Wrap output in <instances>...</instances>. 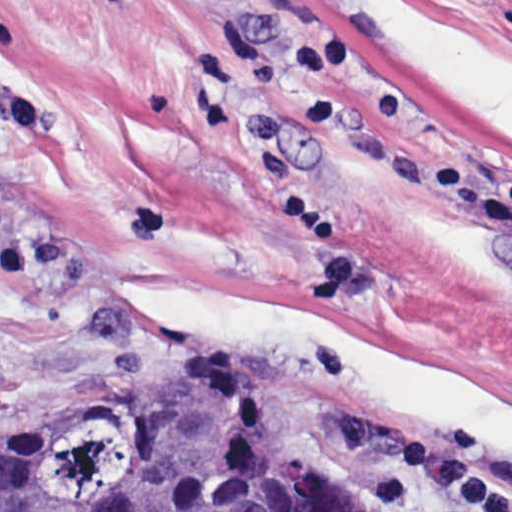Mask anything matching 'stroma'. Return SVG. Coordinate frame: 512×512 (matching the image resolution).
I'll return each mask as SVG.
<instances>
[{
	"instance_id": "35a3bbf8",
	"label": "stroma",
	"mask_w": 512,
	"mask_h": 512,
	"mask_svg": "<svg viewBox=\"0 0 512 512\" xmlns=\"http://www.w3.org/2000/svg\"><path fill=\"white\" fill-rule=\"evenodd\" d=\"M246 384L365 512L512 488V0H0V454Z\"/></svg>"
}]
</instances>
